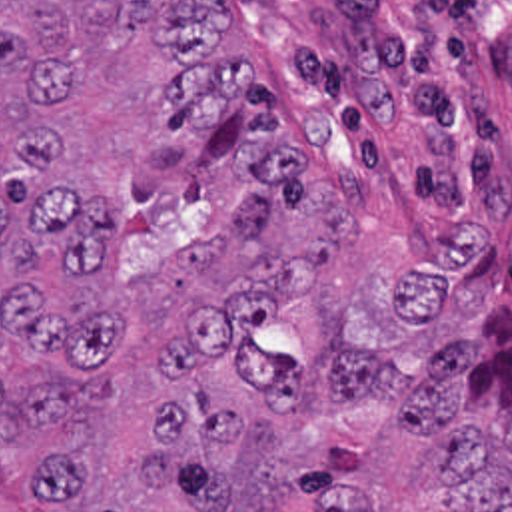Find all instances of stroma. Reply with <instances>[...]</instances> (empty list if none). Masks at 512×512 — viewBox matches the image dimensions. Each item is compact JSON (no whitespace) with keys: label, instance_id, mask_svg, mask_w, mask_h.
<instances>
[{"label":"stroma","instance_id":"obj_1","mask_svg":"<svg viewBox=\"0 0 512 512\" xmlns=\"http://www.w3.org/2000/svg\"><path fill=\"white\" fill-rule=\"evenodd\" d=\"M290 145L354 213L330 281L286 304L266 350L306 370L304 424L358 450L372 512H450L428 448L376 404L328 410L340 338L418 366L488 308H512V0H222Z\"/></svg>","mask_w":512,"mask_h":512}]
</instances>
